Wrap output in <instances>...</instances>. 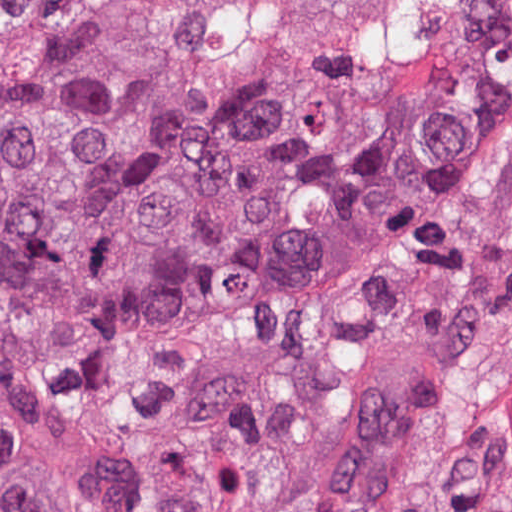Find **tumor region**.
Segmentation results:
<instances>
[{
  "label": "tumor region",
  "instance_id": "tumor-region-1",
  "mask_svg": "<svg viewBox=\"0 0 512 512\" xmlns=\"http://www.w3.org/2000/svg\"><path fill=\"white\" fill-rule=\"evenodd\" d=\"M512 231V0H0V512H325Z\"/></svg>",
  "mask_w": 512,
  "mask_h": 512
}]
</instances>
